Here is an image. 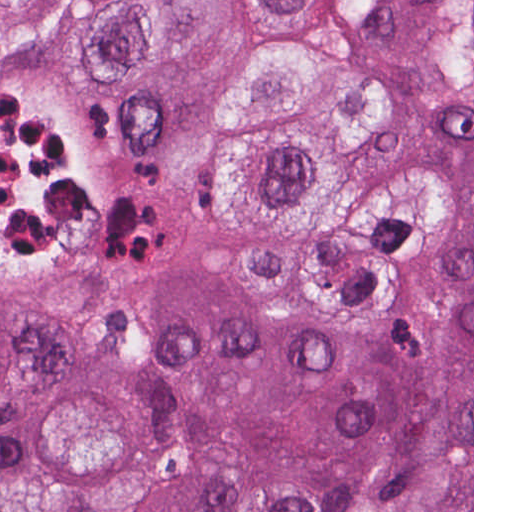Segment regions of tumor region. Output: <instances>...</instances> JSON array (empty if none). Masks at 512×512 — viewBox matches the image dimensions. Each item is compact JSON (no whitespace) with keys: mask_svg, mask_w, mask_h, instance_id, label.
Segmentation results:
<instances>
[{"mask_svg":"<svg viewBox=\"0 0 512 512\" xmlns=\"http://www.w3.org/2000/svg\"><path fill=\"white\" fill-rule=\"evenodd\" d=\"M79 99L128 232L0 274V512H472V0H144Z\"/></svg>","mask_w":512,"mask_h":512,"instance_id":"1","label":"tumor region"}]
</instances>
